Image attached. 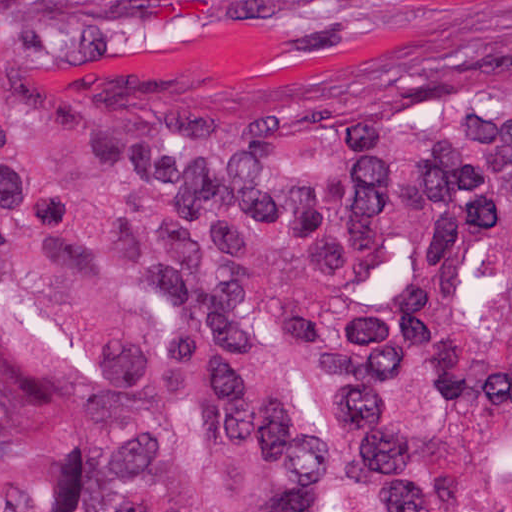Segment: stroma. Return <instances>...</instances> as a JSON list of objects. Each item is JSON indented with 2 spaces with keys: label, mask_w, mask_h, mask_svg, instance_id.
I'll return each mask as SVG.
<instances>
[{
  "label": "stroma",
  "mask_w": 512,
  "mask_h": 512,
  "mask_svg": "<svg viewBox=\"0 0 512 512\" xmlns=\"http://www.w3.org/2000/svg\"><path fill=\"white\" fill-rule=\"evenodd\" d=\"M95 48L171 71H229L351 48L445 0H34Z\"/></svg>",
  "instance_id": "stroma-1"
}]
</instances>
